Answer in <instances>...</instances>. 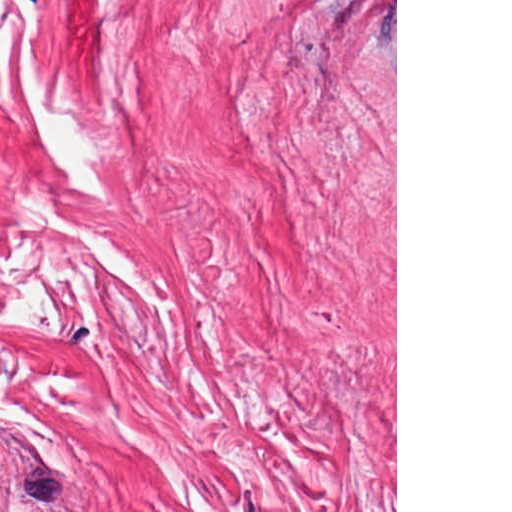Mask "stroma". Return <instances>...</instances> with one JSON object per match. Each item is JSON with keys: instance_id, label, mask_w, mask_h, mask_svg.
Listing matches in <instances>:
<instances>
[{"instance_id": "stroma-1", "label": "stroma", "mask_w": 512, "mask_h": 512, "mask_svg": "<svg viewBox=\"0 0 512 512\" xmlns=\"http://www.w3.org/2000/svg\"><path fill=\"white\" fill-rule=\"evenodd\" d=\"M386 0H0V487L332 512Z\"/></svg>"}]
</instances>
